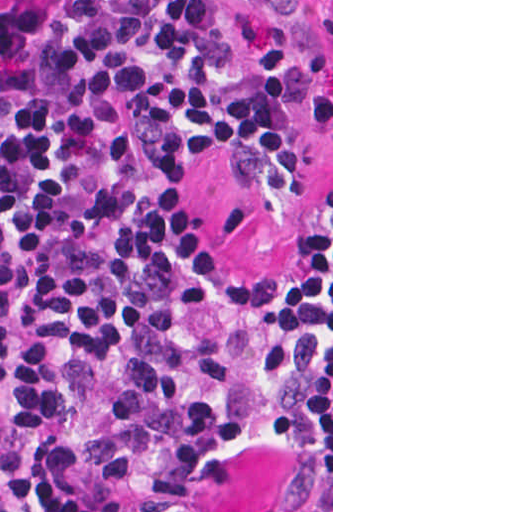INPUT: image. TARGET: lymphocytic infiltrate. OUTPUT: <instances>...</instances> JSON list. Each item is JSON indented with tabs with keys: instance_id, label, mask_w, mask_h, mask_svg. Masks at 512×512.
<instances>
[{
	"instance_id": "f902f5d3",
	"label": "lymphocytic infiltrate",
	"mask_w": 512,
	"mask_h": 512,
	"mask_svg": "<svg viewBox=\"0 0 512 512\" xmlns=\"http://www.w3.org/2000/svg\"><path fill=\"white\" fill-rule=\"evenodd\" d=\"M224 0H0V512H217L260 398L331 362V209L293 279L205 236L218 152L304 200L289 92ZM272 512H331L292 464Z\"/></svg>"
}]
</instances>
